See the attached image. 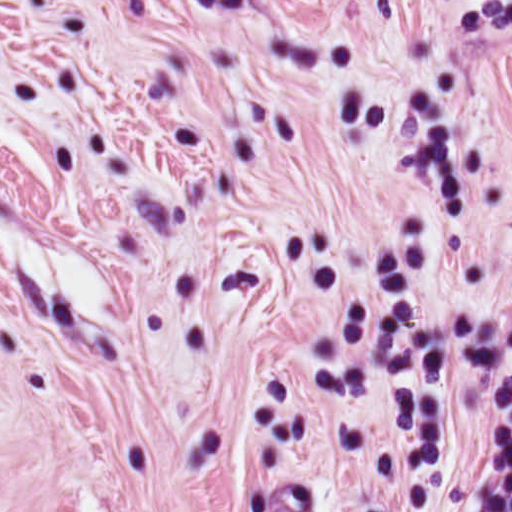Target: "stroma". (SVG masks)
Returning a JSON list of instances; mask_svg holds the SVG:
<instances>
[{
    "instance_id": "1",
    "label": "stroma",
    "mask_w": 512,
    "mask_h": 512,
    "mask_svg": "<svg viewBox=\"0 0 512 512\" xmlns=\"http://www.w3.org/2000/svg\"><path fill=\"white\" fill-rule=\"evenodd\" d=\"M512 229L0 456V512H439Z\"/></svg>"
}]
</instances>
